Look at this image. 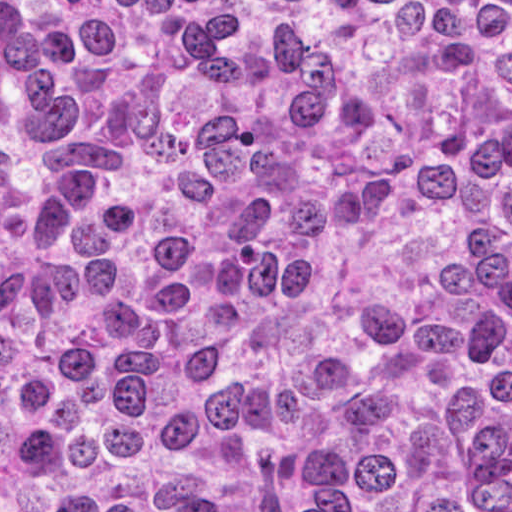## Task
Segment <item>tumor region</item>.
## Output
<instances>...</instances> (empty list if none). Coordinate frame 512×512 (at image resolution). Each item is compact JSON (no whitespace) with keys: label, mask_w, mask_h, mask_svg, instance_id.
Returning <instances> with one entry per match:
<instances>
[{"label":"tumor region","mask_w":512,"mask_h":512,"mask_svg":"<svg viewBox=\"0 0 512 512\" xmlns=\"http://www.w3.org/2000/svg\"><path fill=\"white\" fill-rule=\"evenodd\" d=\"M0 512H512V0H0Z\"/></svg>","instance_id":"obj_1"}]
</instances>
